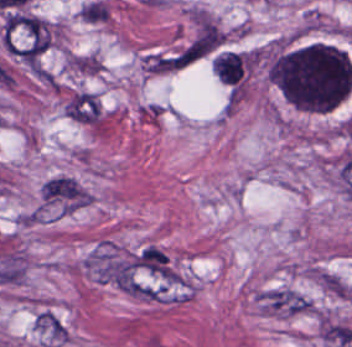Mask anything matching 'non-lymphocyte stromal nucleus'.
Masks as SVG:
<instances>
[{
  "label": "non-lymphocyte stromal nucleus",
  "instance_id": "non-lymphocyte-stromal-nucleus-1",
  "mask_svg": "<svg viewBox=\"0 0 352 347\" xmlns=\"http://www.w3.org/2000/svg\"><path fill=\"white\" fill-rule=\"evenodd\" d=\"M206 37L195 36L144 51L140 68L145 73L166 74L185 68L208 53Z\"/></svg>",
  "mask_w": 352,
  "mask_h": 347
},
{
  "label": "non-lymphocyte stromal nucleus",
  "instance_id": "non-lymphocyte-stromal-nucleus-2",
  "mask_svg": "<svg viewBox=\"0 0 352 347\" xmlns=\"http://www.w3.org/2000/svg\"><path fill=\"white\" fill-rule=\"evenodd\" d=\"M260 310L272 316H290L313 311L310 297L301 291L284 285L258 290L254 294Z\"/></svg>",
  "mask_w": 352,
  "mask_h": 347
},
{
  "label": "non-lymphocyte stromal nucleus",
  "instance_id": "non-lymphocyte-stromal-nucleus-3",
  "mask_svg": "<svg viewBox=\"0 0 352 347\" xmlns=\"http://www.w3.org/2000/svg\"><path fill=\"white\" fill-rule=\"evenodd\" d=\"M99 112L96 97L87 90H79L64 104V114L83 122H96Z\"/></svg>",
  "mask_w": 352,
  "mask_h": 347
},
{
  "label": "non-lymphocyte stromal nucleus",
  "instance_id": "non-lymphocyte-stromal-nucleus-4",
  "mask_svg": "<svg viewBox=\"0 0 352 347\" xmlns=\"http://www.w3.org/2000/svg\"><path fill=\"white\" fill-rule=\"evenodd\" d=\"M37 79L52 90H58L60 81L58 77L47 67L39 65L33 72Z\"/></svg>",
  "mask_w": 352,
  "mask_h": 347
}]
</instances>
